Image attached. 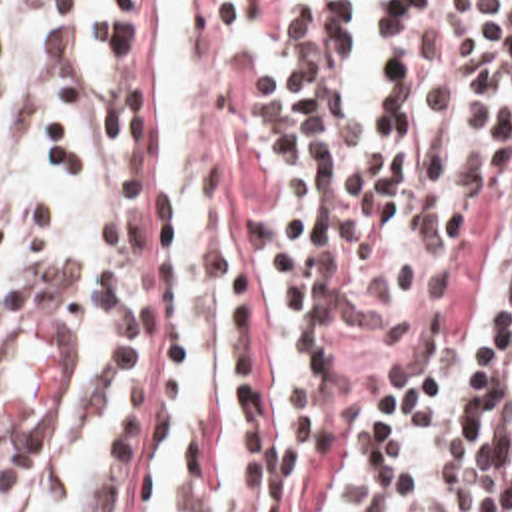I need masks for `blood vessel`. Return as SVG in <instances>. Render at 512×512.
<instances>
[{
    "mask_svg": "<svg viewBox=\"0 0 512 512\" xmlns=\"http://www.w3.org/2000/svg\"><path fill=\"white\" fill-rule=\"evenodd\" d=\"M51 312L17 320L0 344V453L53 459L72 441L88 397L90 358Z\"/></svg>",
    "mask_w": 512,
    "mask_h": 512,
    "instance_id": "blood-vessel-1",
    "label": "blood vessel"
}]
</instances>
